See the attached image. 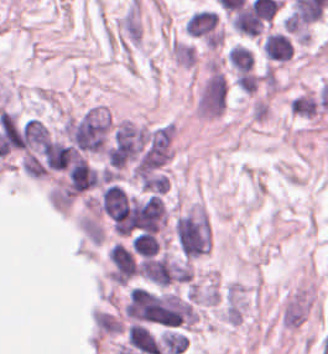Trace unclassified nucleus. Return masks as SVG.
Masks as SVG:
<instances>
[{"label":"unclassified nucleus","mask_w":328,"mask_h":354,"mask_svg":"<svg viewBox=\"0 0 328 354\" xmlns=\"http://www.w3.org/2000/svg\"><path fill=\"white\" fill-rule=\"evenodd\" d=\"M264 52L270 61H289L293 50L291 39L288 35L278 31H271L263 42Z\"/></svg>","instance_id":"unclassified-nucleus-1"},{"label":"unclassified nucleus","mask_w":328,"mask_h":354,"mask_svg":"<svg viewBox=\"0 0 328 354\" xmlns=\"http://www.w3.org/2000/svg\"><path fill=\"white\" fill-rule=\"evenodd\" d=\"M231 67L237 75H244L252 69L253 53L251 49L242 44L231 46L228 52Z\"/></svg>","instance_id":"unclassified-nucleus-2"}]
</instances>
